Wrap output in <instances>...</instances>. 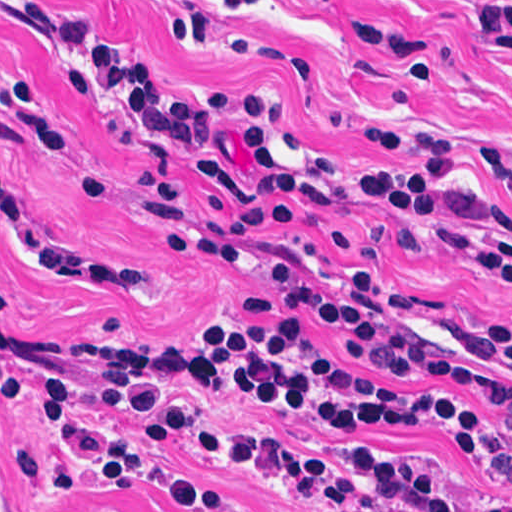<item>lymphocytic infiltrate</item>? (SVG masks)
Listing matches in <instances>:
<instances>
[{
    "instance_id": "1",
    "label": "lymphocytic infiltrate",
    "mask_w": 512,
    "mask_h": 512,
    "mask_svg": "<svg viewBox=\"0 0 512 512\" xmlns=\"http://www.w3.org/2000/svg\"><path fill=\"white\" fill-rule=\"evenodd\" d=\"M0 11L49 38L63 52L58 65L70 87L106 131H125L144 143L145 168L135 180L145 212L159 229L167 254L204 266L239 270L261 227L293 230L304 216L340 199L380 203L400 215L392 239L421 256L460 261L512 283V270L412 205L370 186L302 169L283 127L274 95L218 91L193 100L174 97L129 53L111 44L86 17L46 0H0ZM340 129L345 125L338 123ZM381 158H416L417 170L366 167L379 181L440 199L452 177L455 140L414 132L360 130ZM23 145L58 156L81 201L99 199L106 175L76 163L50 116L34 74L0 68V148ZM491 180L512 202V158L483 148ZM489 220L511 226L483 210ZM0 229L29 273L48 271L83 288H142L153 280L147 265H100L81 260L33 234L0 166ZM327 239L346 260L320 261L299 248H282L268 290L242 295L249 316L275 324H235L216 306L211 316L173 344L129 333L119 319L101 325L100 340L70 333H24L1 321L15 296L0 272V336L61 367L78 369H180L235 353L274 330L317 340L355 372L404 389H439L472 402L495 421L512 415V326L481 325L452 316L432 297L407 287L378 267L360 237L331 229ZM0 402L33 410L0 382ZM331 433H401L313 427ZM52 445L64 446L48 428ZM487 483H477L431 452L397 446L312 449L327 462L286 440L227 428L220 421L165 442L126 483L101 487L105 495L137 492L169 512H242L235 500L175 475L164 461L173 449L205 457L312 512H512V444L494 442L488 455L465 439ZM421 470L457 487H470L495 506H469ZM79 491L64 467L51 479Z\"/></svg>"
}]
</instances>
